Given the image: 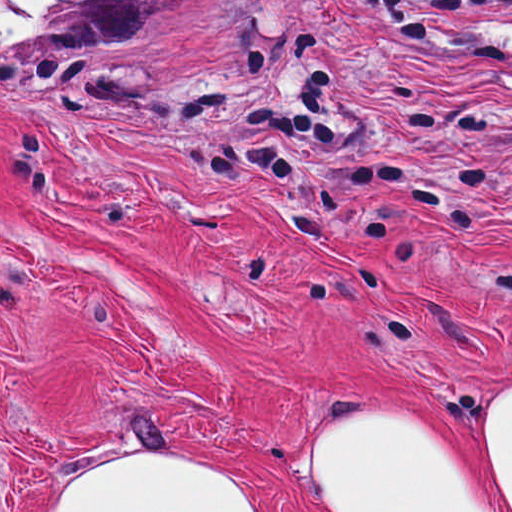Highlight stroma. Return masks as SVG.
I'll list each match as a JSON object with an SVG mask.
<instances>
[{"label":"stroma","mask_w":512,"mask_h":512,"mask_svg":"<svg viewBox=\"0 0 512 512\" xmlns=\"http://www.w3.org/2000/svg\"><path fill=\"white\" fill-rule=\"evenodd\" d=\"M215 0L151 42L0 59V512L187 457L252 512H348L354 408L504 492L512 0Z\"/></svg>","instance_id":"stroma-1"}]
</instances>
